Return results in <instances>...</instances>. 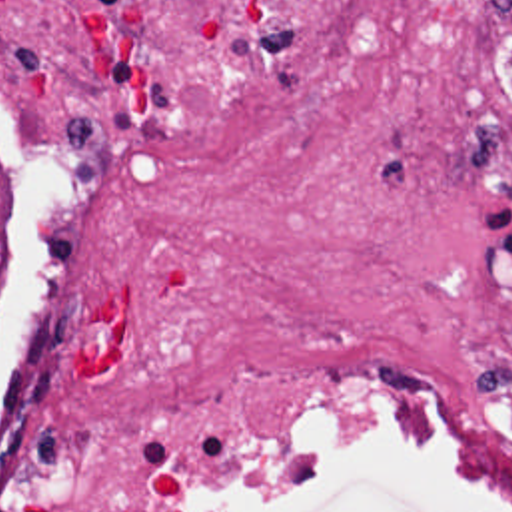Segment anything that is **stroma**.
<instances>
[{"mask_svg": "<svg viewBox=\"0 0 512 512\" xmlns=\"http://www.w3.org/2000/svg\"><path fill=\"white\" fill-rule=\"evenodd\" d=\"M49 203L45 161L0 107V362L31 285ZM245 512H501L449 484L413 428L347 424Z\"/></svg>", "mask_w": 512, "mask_h": 512, "instance_id": "stroma-1", "label": "stroma"}]
</instances>
